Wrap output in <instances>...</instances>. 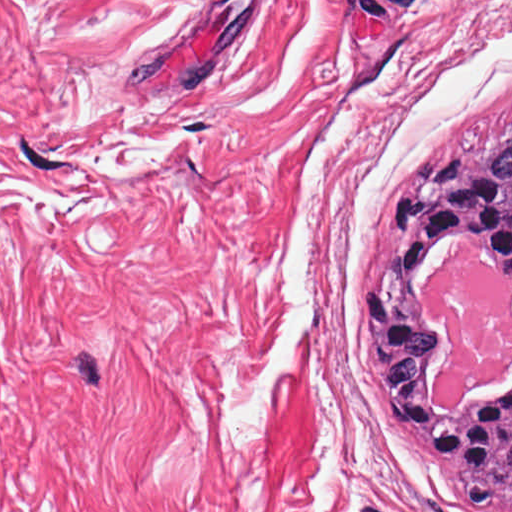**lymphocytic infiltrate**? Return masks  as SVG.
I'll use <instances>...</instances> for the list:
<instances>
[{"instance_id": "1", "label": "lymphocytic infiltrate", "mask_w": 512, "mask_h": 512, "mask_svg": "<svg viewBox=\"0 0 512 512\" xmlns=\"http://www.w3.org/2000/svg\"><path fill=\"white\" fill-rule=\"evenodd\" d=\"M361 313L377 333L378 351L375 363V377L378 386L385 394L390 409L397 416L407 421L425 420V418L411 405L403 390L393 388L387 380V372L391 367V362L385 346V325L387 314V297L385 294L378 290H367L361 303ZM428 445L433 451L442 455L437 449L436 435L433 430L430 433Z\"/></svg>"}]
</instances>
